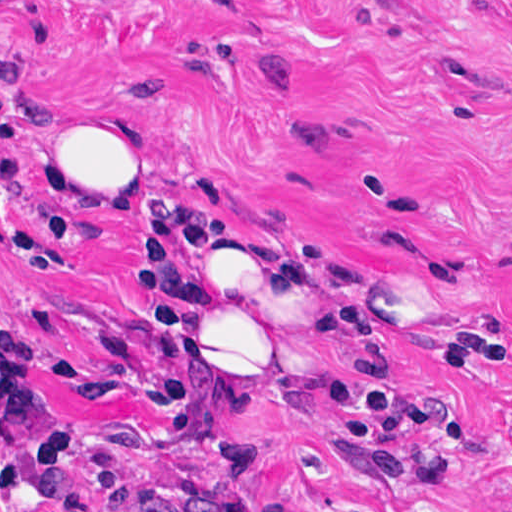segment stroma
Returning <instances> with one entry per match:
<instances>
[{
    "instance_id": "35a3bbf8",
    "label": "stroma",
    "mask_w": 512,
    "mask_h": 512,
    "mask_svg": "<svg viewBox=\"0 0 512 512\" xmlns=\"http://www.w3.org/2000/svg\"><path fill=\"white\" fill-rule=\"evenodd\" d=\"M0 321L39 332L38 385L70 407L76 477L216 487L222 469L135 397L147 349L135 182L212 145L303 218L342 394L399 392L402 480L286 374L227 416L255 461L248 512H512V0H0ZM148 116L142 177L46 199L60 107ZM44 204L73 211L75 235ZM177 261L163 322L229 386L202 285ZM37 512H55L49 508Z\"/></svg>"
}]
</instances>
